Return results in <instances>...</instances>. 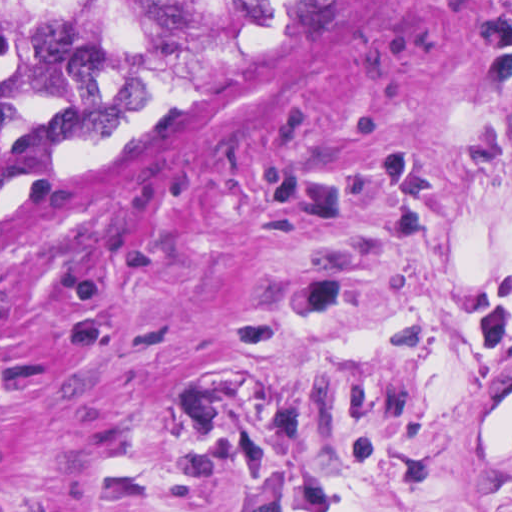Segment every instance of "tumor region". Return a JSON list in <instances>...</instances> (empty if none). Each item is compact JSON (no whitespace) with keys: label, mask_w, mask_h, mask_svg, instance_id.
I'll use <instances>...</instances> for the list:
<instances>
[{"label":"tumor region","mask_w":512,"mask_h":512,"mask_svg":"<svg viewBox=\"0 0 512 512\" xmlns=\"http://www.w3.org/2000/svg\"><path fill=\"white\" fill-rule=\"evenodd\" d=\"M337 1L0 0V195L120 114L251 57Z\"/></svg>","instance_id":"e687c5a6"}]
</instances>
